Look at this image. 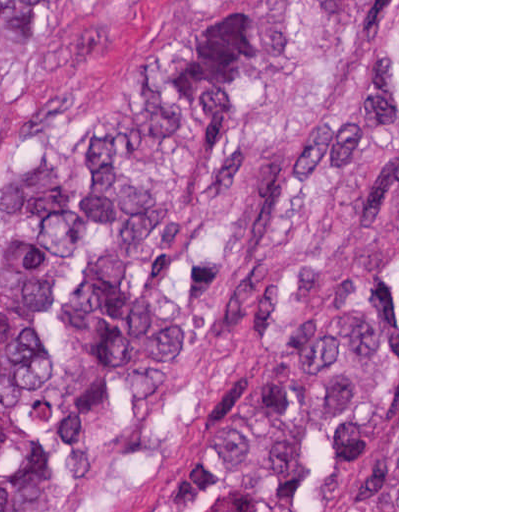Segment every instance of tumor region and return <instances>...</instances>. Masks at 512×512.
Instances as JSON below:
<instances>
[{
    "mask_svg": "<svg viewBox=\"0 0 512 512\" xmlns=\"http://www.w3.org/2000/svg\"><path fill=\"white\" fill-rule=\"evenodd\" d=\"M214 7L224 0H196ZM0 0L10 79L60 23ZM397 135V0H249L0 165V512L85 490L233 293ZM142 512H397V227L300 283L168 452Z\"/></svg>",
    "mask_w": 512,
    "mask_h": 512,
    "instance_id": "1",
    "label": "tumor region"
}]
</instances>
